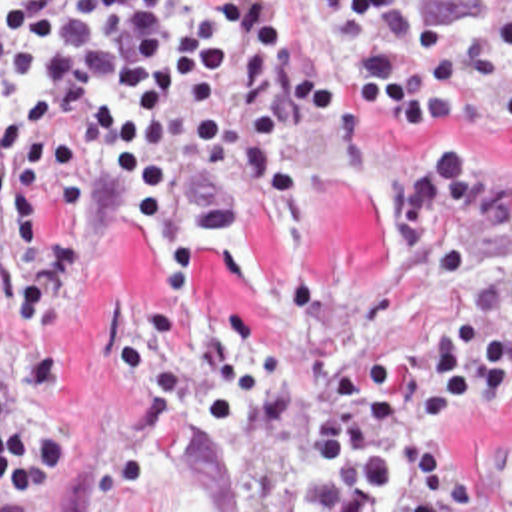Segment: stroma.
<instances>
[{
	"label": "stroma",
	"instance_id": "35a3bbf8",
	"mask_svg": "<svg viewBox=\"0 0 512 512\" xmlns=\"http://www.w3.org/2000/svg\"><path fill=\"white\" fill-rule=\"evenodd\" d=\"M215 4V0H199ZM503 0H421L433 24L485 26ZM453 144L495 150L512 168V122L447 120L399 132L373 108L301 124L289 154L311 190L303 226L247 188L235 236L203 230L201 202L177 192L203 284L179 304L165 254L133 222L99 214L89 182L87 254L55 338L75 380L43 408L69 456L39 512H329L357 469H313L307 428L339 396L347 346L415 380L423 344L447 320L512 298V260L479 220H459L417 256H397L389 192ZM443 463L471 471L465 512H512V382L477 418L445 432Z\"/></svg>",
	"mask_w": 512,
	"mask_h": 512
}]
</instances>
